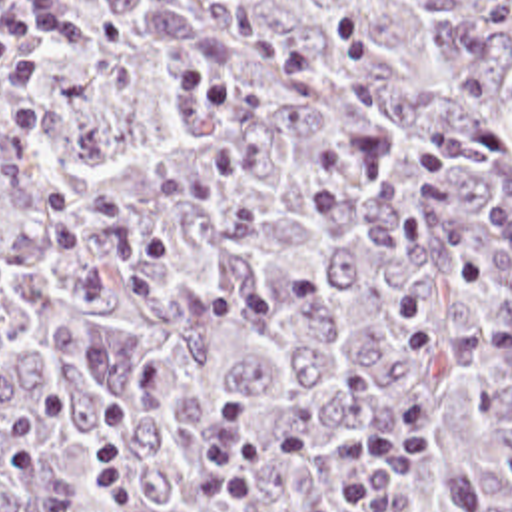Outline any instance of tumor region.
Wrapping results in <instances>:
<instances>
[{"label": "tumor region", "instance_id": "e687c5a6", "mask_svg": "<svg viewBox=\"0 0 512 512\" xmlns=\"http://www.w3.org/2000/svg\"><path fill=\"white\" fill-rule=\"evenodd\" d=\"M408 393L406 512H512V0H67L0 75V512H314L350 469L201 504L229 403L350 437Z\"/></svg>", "mask_w": 512, "mask_h": 512}]
</instances>
